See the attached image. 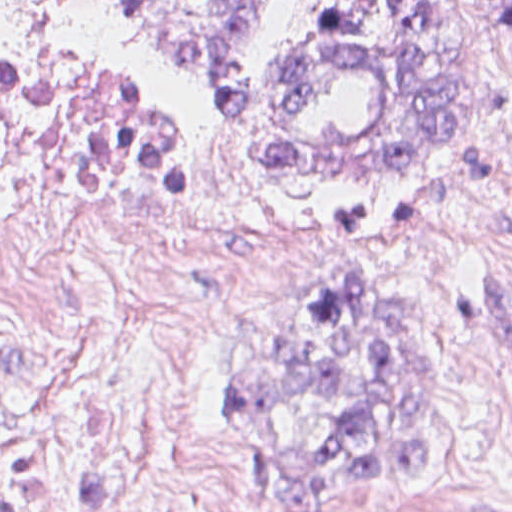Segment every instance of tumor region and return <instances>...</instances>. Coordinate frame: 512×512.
Returning a JSON list of instances; mask_svg holds the SVG:
<instances>
[{
	"instance_id": "tumor-region-1",
	"label": "tumor region",
	"mask_w": 512,
	"mask_h": 512,
	"mask_svg": "<svg viewBox=\"0 0 512 512\" xmlns=\"http://www.w3.org/2000/svg\"><path fill=\"white\" fill-rule=\"evenodd\" d=\"M147 38L214 92L252 157L286 176H382L435 162L477 96L479 0H132ZM512 37V0H488ZM437 346L371 275L293 299L278 348L231 375L237 442L297 512L427 476ZM490 512H512L493 510Z\"/></svg>"
}]
</instances>
